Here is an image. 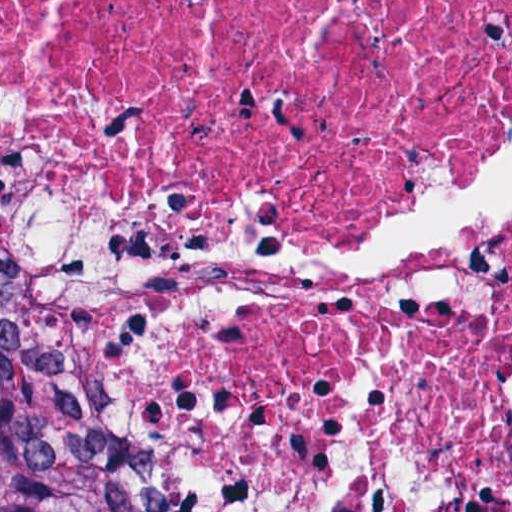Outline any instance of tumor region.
<instances>
[{
    "label": "tumor region",
    "instance_id": "e687c5a6",
    "mask_svg": "<svg viewBox=\"0 0 512 512\" xmlns=\"http://www.w3.org/2000/svg\"><path fill=\"white\" fill-rule=\"evenodd\" d=\"M0 512H152L74 323L2 266Z\"/></svg>",
    "mask_w": 512,
    "mask_h": 512
}]
</instances>
